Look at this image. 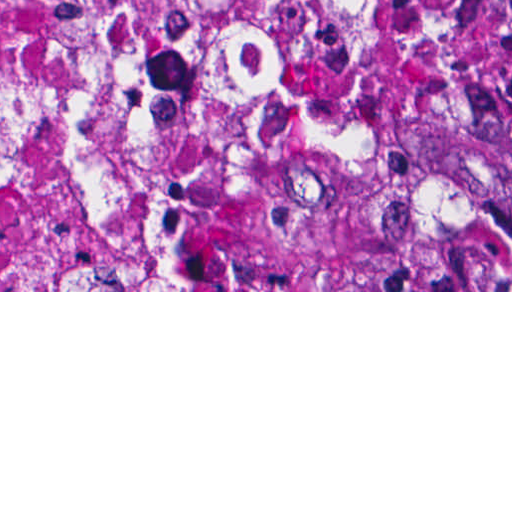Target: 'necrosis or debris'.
<instances>
[{
  "instance_id": "1",
  "label": "necrosis or debris",
  "mask_w": 512,
  "mask_h": 512,
  "mask_svg": "<svg viewBox=\"0 0 512 512\" xmlns=\"http://www.w3.org/2000/svg\"><path fill=\"white\" fill-rule=\"evenodd\" d=\"M511 146L463 0H0V290H512Z\"/></svg>"
}]
</instances>
